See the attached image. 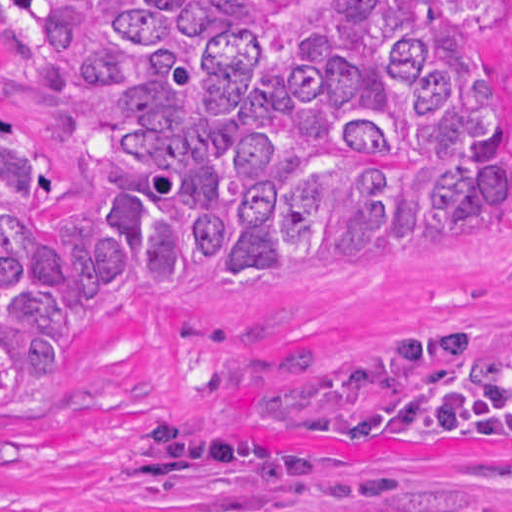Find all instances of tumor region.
<instances>
[{
    "label": "tumor region",
    "mask_w": 512,
    "mask_h": 512,
    "mask_svg": "<svg viewBox=\"0 0 512 512\" xmlns=\"http://www.w3.org/2000/svg\"><path fill=\"white\" fill-rule=\"evenodd\" d=\"M499 0H0V42L73 87L98 228L27 200L54 184L0 129V414L82 362L90 305L239 304L283 279L414 258L463 218L512 226ZM253 428L430 455L512 445V320L441 330L240 395ZM175 419L134 432V484L215 463L390 496L269 436Z\"/></svg>",
    "instance_id": "tumor-region-1"
}]
</instances>
